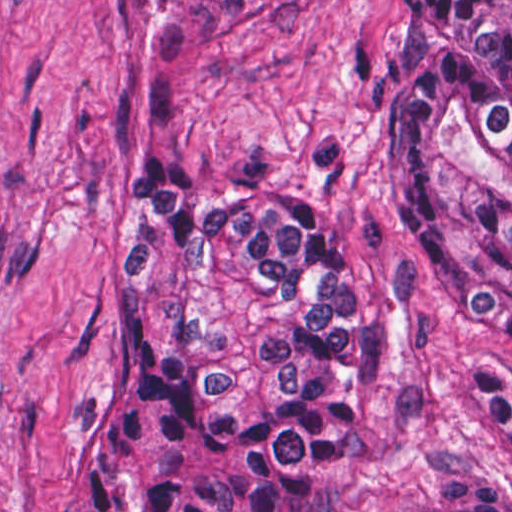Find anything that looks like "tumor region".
I'll return each mask as SVG.
<instances>
[{"mask_svg": "<svg viewBox=\"0 0 512 512\" xmlns=\"http://www.w3.org/2000/svg\"><path fill=\"white\" fill-rule=\"evenodd\" d=\"M174 1L231 19L266 0ZM386 93L455 296L512 367V0H401ZM112 302L124 402L73 512H326L376 383L377 289L315 204L132 180ZM416 512H512V484Z\"/></svg>", "mask_w": 512, "mask_h": 512, "instance_id": "obj_1", "label": "tumor region"}]
</instances>
